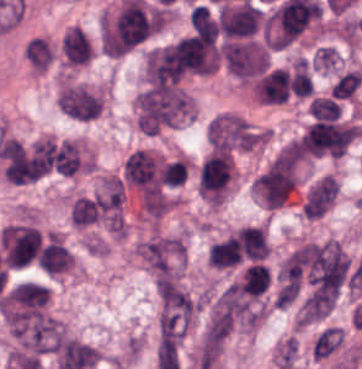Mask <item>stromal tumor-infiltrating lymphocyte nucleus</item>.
Instances as JSON below:
<instances>
[{
  "label": "stromal tumor-infiltrating lymphocyte nucleus",
  "instance_id": "obj_1",
  "mask_svg": "<svg viewBox=\"0 0 362 369\" xmlns=\"http://www.w3.org/2000/svg\"><path fill=\"white\" fill-rule=\"evenodd\" d=\"M36 263L49 275H56L73 266V254L58 238H51L41 248Z\"/></svg>",
  "mask_w": 362,
  "mask_h": 369
},
{
  "label": "stromal tumor-infiltrating lymphocyte nucleus",
  "instance_id": "obj_2",
  "mask_svg": "<svg viewBox=\"0 0 362 369\" xmlns=\"http://www.w3.org/2000/svg\"><path fill=\"white\" fill-rule=\"evenodd\" d=\"M101 216L100 195H81L73 199L68 211V219L73 227L87 228Z\"/></svg>",
  "mask_w": 362,
  "mask_h": 369
},
{
  "label": "stromal tumor-infiltrating lymphocyte nucleus",
  "instance_id": "obj_3",
  "mask_svg": "<svg viewBox=\"0 0 362 369\" xmlns=\"http://www.w3.org/2000/svg\"><path fill=\"white\" fill-rule=\"evenodd\" d=\"M241 259L239 244L231 234L210 247L209 261L221 269L237 265Z\"/></svg>",
  "mask_w": 362,
  "mask_h": 369
},
{
  "label": "stromal tumor-infiltrating lymphocyte nucleus",
  "instance_id": "obj_4",
  "mask_svg": "<svg viewBox=\"0 0 362 369\" xmlns=\"http://www.w3.org/2000/svg\"><path fill=\"white\" fill-rule=\"evenodd\" d=\"M270 273L264 265L253 264L243 274L241 293L259 296L269 287Z\"/></svg>",
  "mask_w": 362,
  "mask_h": 369
},
{
  "label": "stromal tumor-infiltrating lymphocyte nucleus",
  "instance_id": "obj_5",
  "mask_svg": "<svg viewBox=\"0 0 362 369\" xmlns=\"http://www.w3.org/2000/svg\"><path fill=\"white\" fill-rule=\"evenodd\" d=\"M190 26L201 36L215 42L218 36V25L214 17L204 5L192 8L189 14Z\"/></svg>",
  "mask_w": 362,
  "mask_h": 369
},
{
  "label": "stromal tumor-infiltrating lymphocyte nucleus",
  "instance_id": "obj_6",
  "mask_svg": "<svg viewBox=\"0 0 362 369\" xmlns=\"http://www.w3.org/2000/svg\"><path fill=\"white\" fill-rule=\"evenodd\" d=\"M290 89L293 94L310 96L313 84L305 57H298L292 67L290 75Z\"/></svg>",
  "mask_w": 362,
  "mask_h": 369
},
{
  "label": "stromal tumor-infiltrating lymphocyte nucleus",
  "instance_id": "obj_7",
  "mask_svg": "<svg viewBox=\"0 0 362 369\" xmlns=\"http://www.w3.org/2000/svg\"><path fill=\"white\" fill-rule=\"evenodd\" d=\"M362 81V74L357 69H349L332 85L331 96L336 100L350 96Z\"/></svg>",
  "mask_w": 362,
  "mask_h": 369
},
{
  "label": "stromal tumor-infiltrating lymphocyte nucleus",
  "instance_id": "obj_8",
  "mask_svg": "<svg viewBox=\"0 0 362 369\" xmlns=\"http://www.w3.org/2000/svg\"><path fill=\"white\" fill-rule=\"evenodd\" d=\"M310 111L315 118L336 119L342 111V106L327 96H314Z\"/></svg>",
  "mask_w": 362,
  "mask_h": 369
},
{
  "label": "stromal tumor-infiltrating lymphocyte nucleus",
  "instance_id": "obj_9",
  "mask_svg": "<svg viewBox=\"0 0 362 369\" xmlns=\"http://www.w3.org/2000/svg\"><path fill=\"white\" fill-rule=\"evenodd\" d=\"M186 176V161L177 159L164 163L160 171V180L162 184L179 186Z\"/></svg>",
  "mask_w": 362,
  "mask_h": 369
}]
</instances>
